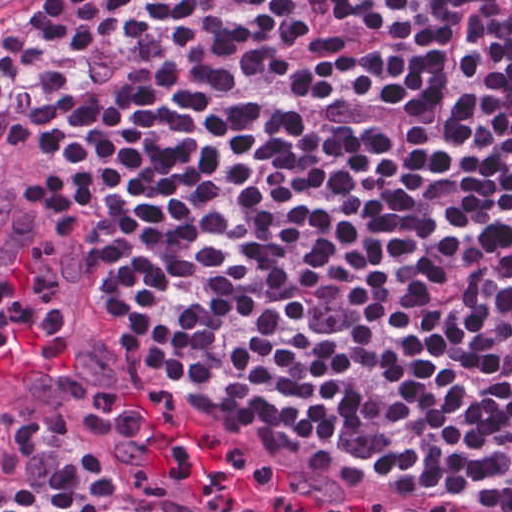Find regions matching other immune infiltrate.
<instances>
[{
  "mask_svg": "<svg viewBox=\"0 0 512 512\" xmlns=\"http://www.w3.org/2000/svg\"><path fill=\"white\" fill-rule=\"evenodd\" d=\"M59 282L51 274L35 280L33 294L22 299L0 291V350L15 338L35 331L57 305Z\"/></svg>",
  "mask_w": 512,
  "mask_h": 512,
  "instance_id": "1",
  "label": "other immune infiltrate"
}]
</instances>
